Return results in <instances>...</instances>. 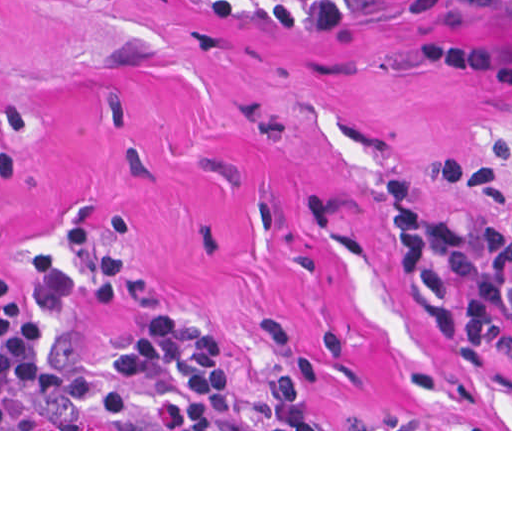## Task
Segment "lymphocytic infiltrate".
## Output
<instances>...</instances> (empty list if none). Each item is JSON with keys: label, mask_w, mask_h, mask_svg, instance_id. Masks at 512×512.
I'll return each mask as SVG.
<instances>
[{"label": "lymphocytic infiltrate", "mask_w": 512, "mask_h": 512, "mask_svg": "<svg viewBox=\"0 0 512 512\" xmlns=\"http://www.w3.org/2000/svg\"><path fill=\"white\" fill-rule=\"evenodd\" d=\"M207 1L272 31H335L388 0ZM17 174L18 153L0 150V186ZM388 202L409 295L487 388H512V215L420 210L402 177ZM44 341L0 274V429H339L293 374L270 397L237 392L218 338L189 315H151L109 353L87 352L76 328L47 354Z\"/></svg>", "instance_id": "f902f5d3"}]
</instances>
